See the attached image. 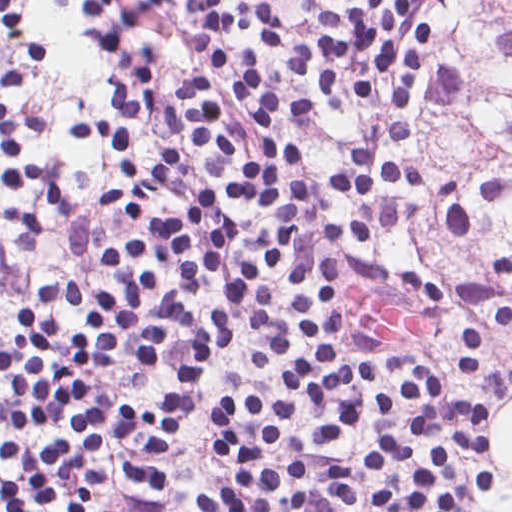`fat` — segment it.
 <instances>
[{
    "instance_id": "obj_1",
    "label": "fat",
    "mask_w": 512,
    "mask_h": 512,
    "mask_svg": "<svg viewBox=\"0 0 512 512\" xmlns=\"http://www.w3.org/2000/svg\"><path fill=\"white\" fill-rule=\"evenodd\" d=\"M498 456L506 462L512 476V416L502 423L498 441ZM495 512H512V497L497 507Z\"/></svg>"
}]
</instances>
